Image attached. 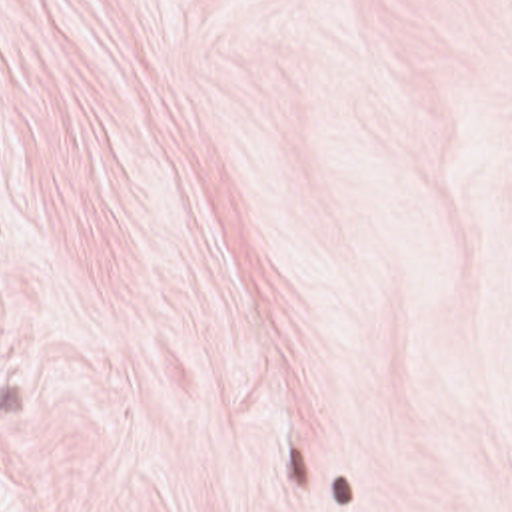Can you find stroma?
<instances>
[{"instance_id":"1","label":"stroma","mask_w":512,"mask_h":512,"mask_svg":"<svg viewBox=\"0 0 512 512\" xmlns=\"http://www.w3.org/2000/svg\"><path fill=\"white\" fill-rule=\"evenodd\" d=\"M0 512H512V0H0Z\"/></svg>"}]
</instances>
